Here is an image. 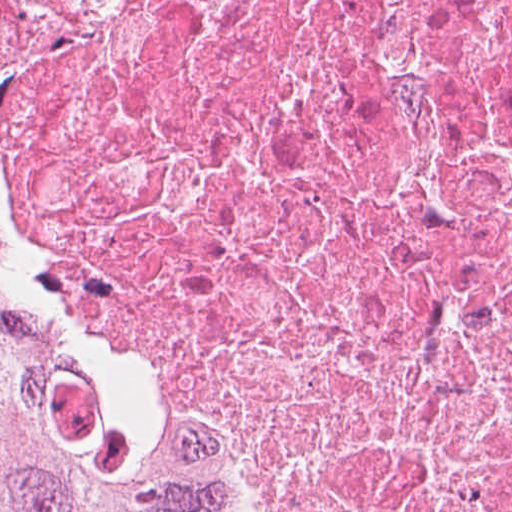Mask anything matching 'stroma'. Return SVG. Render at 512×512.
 <instances>
[{"label": "stroma", "instance_id": "1", "mask_svg": "<svg viewBox=\"0 0 512 512\" xmlns=\"http://www.w3.org/2000/svg\"><path fill=\"white\" fill-rule=\"evenodd\" d=\"M0 233L9 243L10 269L23 284L28 309L129 419L155 439L165 457L188 472L197 491L221 512H272L208 435L182 422L134 413L113 395L81 327L56 308L27 264L1 199Z\"/></svg>", "mask_w": 512, "mask_h": 512}]
</instances>
